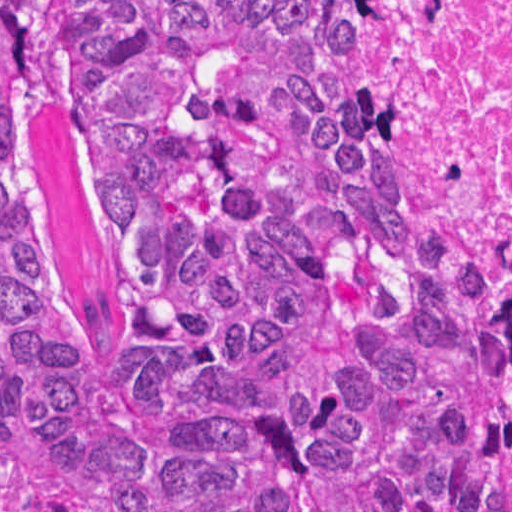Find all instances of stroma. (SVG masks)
Wrapping results in <instances>:
<instances>
[{"label":"stroma","instance_id":"1","mask_svg":"<svg viewBox=\"0 0 512 512\" xmlns=\"http://www.w3.org/2000/svg\"><path fill=\"white\" fill-rule=\"evenodd\" d=\"M371 114L385 137L395 173L418 208L433 218L488 275L512 319V272L508 265L480 241L421 140L372 110Z\"/></svg>","mask_w":512,"mask_h":512}]
</instances>
